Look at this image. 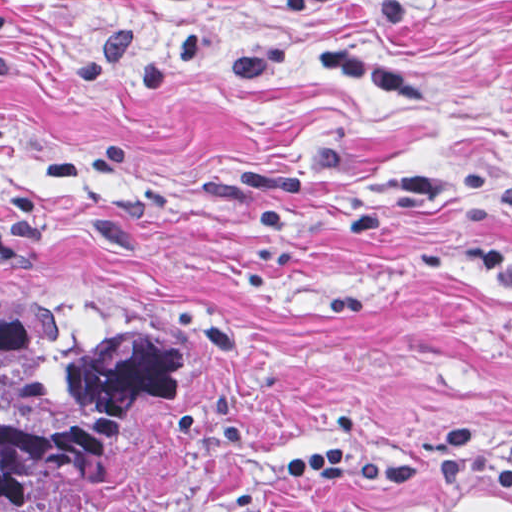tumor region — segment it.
<instances>
[{
  "mask_svg": "<svg viewBox=\"0 0 512 512\" xmlns=\"http://www.w3.org/2000/svg\"><path fill=\"white\" fill-rule=\"evenodd\" d=\"M206 386L203 332H74L0 309V512H78L136 430Z\"/></svg>",
  "mask_w": 512,
  "mask_h": 512,
  "instance_id": "tumor-region-1",
  "label": "tumor region"
}]
</instances>
